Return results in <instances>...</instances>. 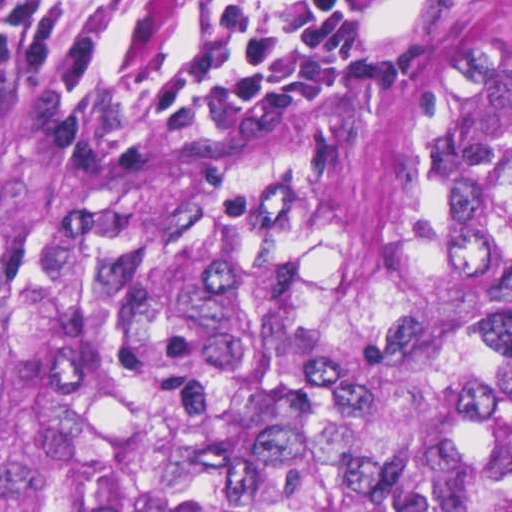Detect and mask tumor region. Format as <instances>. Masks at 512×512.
Wrapping results in <instances>:
<instances>
[{
    "instance_id": "obj_1",
    "label": "tumor region",
    "mask_w": 512,
    "mask_h": 512,
    "mask_svg": "<svg viewBox=\"0 0 512 512\" xmlns=\"http://www.w3.org/2000/svg\"><path fill=\"white\" fill-rule=\"evenodd\" d=\"M0 512H512V0L349 128L0 79Z\"/></svg>"
}]
</instances>
